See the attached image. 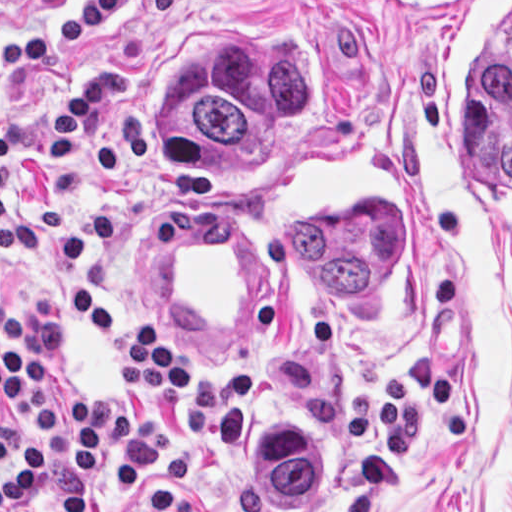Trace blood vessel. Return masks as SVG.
<instances>
[{
	"mask_svg": "<svg viewBox=\"0 0 512 512\" xmlns=\"http://www.w3.org/2000/svg\"><path fill=\"white\" fill-rule=\"evenodd\" d=\"M142 210L136 253L152 304L205 337H249L270 319L274 261L247 214L215 188Z\"/></svg>",
	"mask_w": 512,
	"mask_h": 512,
	"instance_id": "blood-vessel-1",
	"label": "blood vessel"
}]
</instances>
